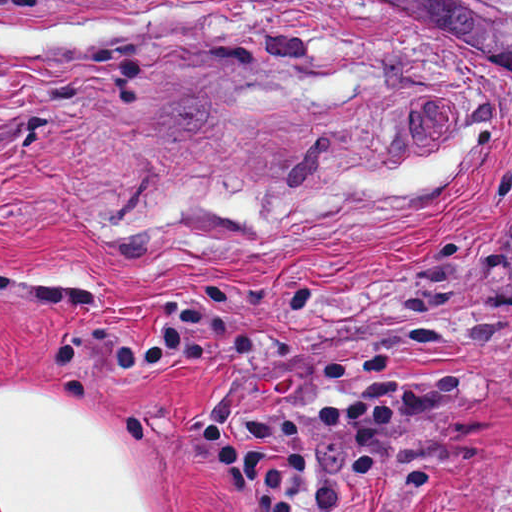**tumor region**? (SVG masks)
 Listing matches in <instances>:
<instances>
[{
  "instance_id": "e687c5a6",
  "label": "tumor region",
  "mask_w": 512,
  "mask_h": 512,
  "mask_svg": "<svg viewBox=\"0 0 512 512\" xmlns=\"http://www.w3.org/2000/svg\"><path fill=\"white\" fill-rule=\"evenodd\" d=\"M346 1L427 27L458 53L512 62V0ZM489 512H512V488Z\"/></svg>"
}]
</instances>
